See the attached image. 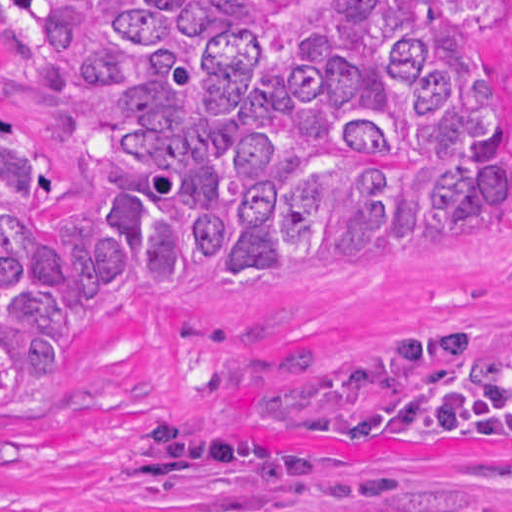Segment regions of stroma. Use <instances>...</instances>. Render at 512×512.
<instances>
[{"label": "stroma", "mask_w": 512, "mask_h": 512, "mask_svg": "<svg viewBox=\"0 0 512 512\" xmlns=\"http://www.w3.org/2000/svg\"><path fill=\"white\" fill-rule=\"evenodd\" d=\"M505 93L512 92V0H499ZM0 129L54 184L27 203L41 222L98 228L73 87L35 80L0 42ZM512 320V226L465 217L414 258L279 280L239 304L144 310L118 286L90 305L84 354L0 414V512H302L351 504L309 486L215 463L165 486L134 484L147 456L134 432L177 417L297 443L345 467L400 473L398 494L428 504L512 506V445L430 455L370 441L253 428L240 395L322 373L384 346Z\"/></svg>", "instance_id": "obj_1"}]
</instances>
